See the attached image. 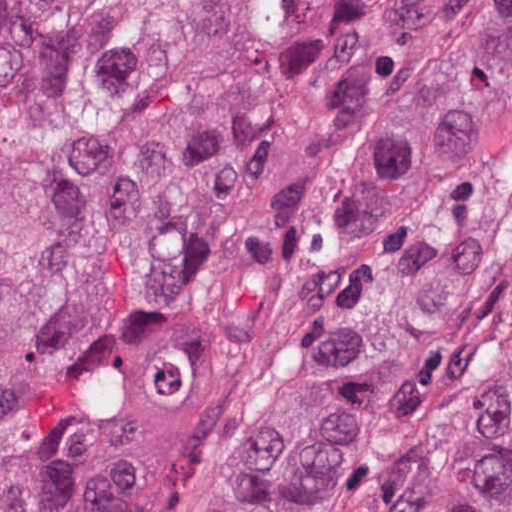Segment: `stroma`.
Instances as JSON below:
<instances>
[{
	"mask_svg": "<svg viewBox=\"0 0 512 512\" xmlns=\"http://www.w3.org/2000/svg\"><path fill=\"white\" fill-rule=\"evenodd\" d=\"M415 212L467 216L473 304L451 379L368 510L388 512L448 423L512 358V98L493 143L473 163L390 205L321 297L246 357H223L206 338H152L135 347L128 370L140 512H207L342 320L388 284L372 288L374 242Z\"/></svg>",
	"mask_w": 512,
	"mask_h": 512,
	"instance_id": "stroma-1",
	"label": "stroma"
}]
</instances>
